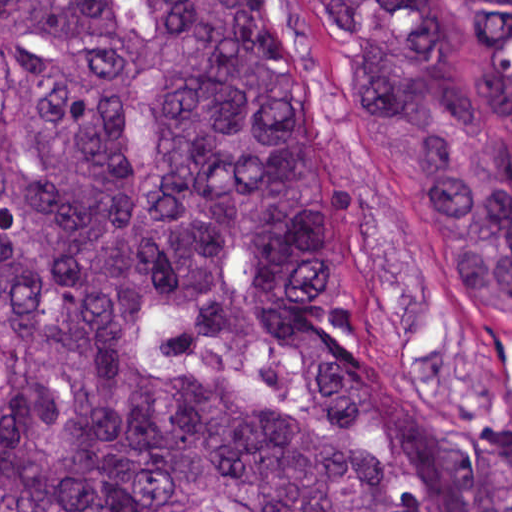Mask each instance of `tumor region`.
<instances>
[{
	"instance_id": "e687c5a6",
	"label": "tumor region",
	"mask_w": 512,
	"mask_h": 512,
	"mask_svg": "<svg viewBox=\"0 0 512 512\" xmlns=\"http://www.w3.org/2000/svg\"><path fill=\"white\" fill-rule=\"evenodd\" d=\"M318 0L452 303L512 329V0ZM0 512H512L338 355L331 158L259 0H0Z\"/></svg>"
}]
</instances>
